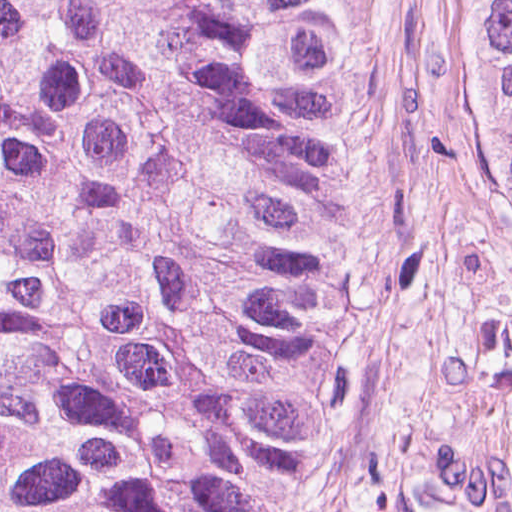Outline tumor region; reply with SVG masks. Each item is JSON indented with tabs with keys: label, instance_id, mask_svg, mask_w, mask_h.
<instances>
[{
	"label": "tumor region",
	"instance_id": "obj_1",
	"mask_svg": "<svg viewBox=\"0 0 512 512\" xmlns=\"http://www.w3.org/2000/svg\"><path fill=\"white\" fill-rule=\"evenodd\" d=\"M360 197L332 0H0V512H287Z\"/></svg>",
	"mask_w": 512,
	"mask_h": 512
}]
</instances>
